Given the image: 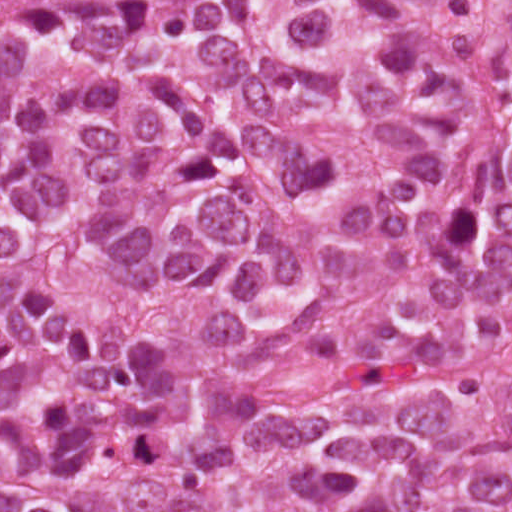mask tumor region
Returning <instances> with one entry per match:
<instances>
[{
    "mask_svg": "<svg viewBox=\"0 0 512 512\" xmlns=\"http://www.w3.org/2000/svg\"><path fill=\"white\" fill-rule=\"evenodd\" d=\"M1 512H512V0H1Z\"/></svg>",
    "mask_w": 512,
    "mask_h": 512,
    "instance_id": "1",
    "label": "tumor region"
}]
</instances>
